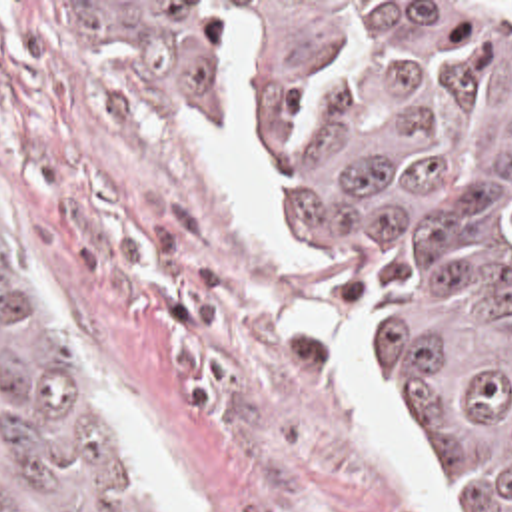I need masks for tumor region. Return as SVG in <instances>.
<instances>
[{"mask_svg":"<svg viewBox=\"0 0 512 512\" xmlns=\"http://www.w3.org/2000/svg\"><path fill=\"white\" fill-rule=\"evenodd\" d=\"M144 110L230 84L224 2H52ZM270 206L364 291L368 361L472 512H512V2H362L256 54ZM0 512H176L0 188Z\"/></svg>","mask_w":512,"mask_h":512,"instance_id":"obj_1","label":"tumor region"}]
</instances>
